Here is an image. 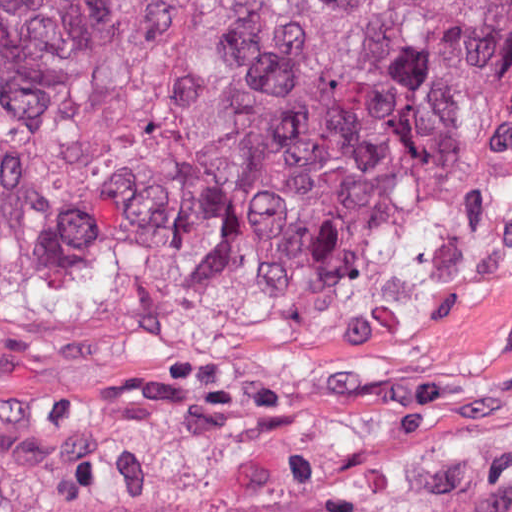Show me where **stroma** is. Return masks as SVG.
Returning <instances> with one entry per match:
<instances>
[{
    "instance_id": "stroma-1",
    "label": "stroma",
    "mask_w": 512,
    "mask_h": 512,
    "mask_svg": "<svg viewBox=\"0 0 512 512\" xmlns=\"http://www.w3.org/2000/svg\"><path fill=\"white\" fill-rule=\"evenodd\" d=\"M451 446H512V268L377 298L209 239L84 308L0 291V512H308Z\"/></svg>"
}]
</instances>
